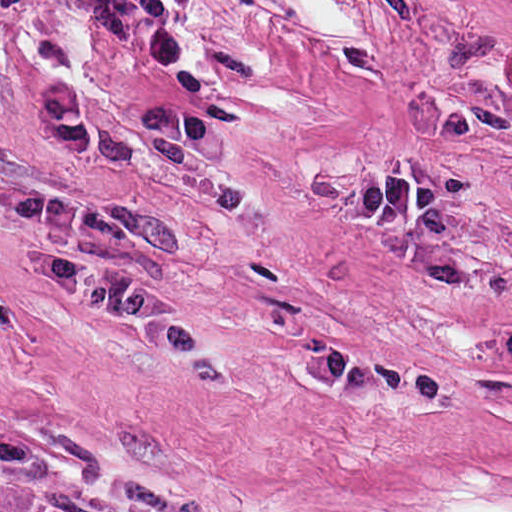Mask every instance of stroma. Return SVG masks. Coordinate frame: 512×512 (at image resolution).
Returning a JSON list of instances; mask_svg holds the SVG:
<instances>
[{
    "mask_svg": "<svg viewBox=\"0 0 512 512\" xmlns=\"http://www.w3.org/2000/svg\"><path fill=\"white\" fill-rule=\"evenodd\" d=\"M164 67L224 186L149 193L512 310V0H184ZM0 144L140 189L1 54Z\"/></svg>",
    "mask_w": 512,
    "mask_h": 512,
    "instance_id": "obj_1",
    "label": "stroma"
}]
</instances>
